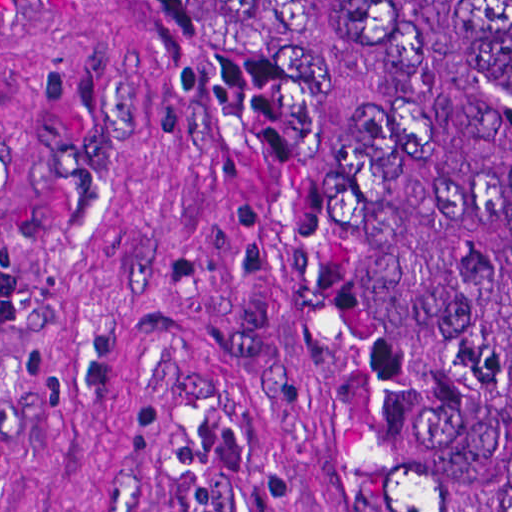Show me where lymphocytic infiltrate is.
I'll return each instance as SVG.
<instances>
[{"instance_id":"obj_1","label":"lymphocytic infiltrate","mask_w":512,"mask_h":512,"mask_svg":"<svg viewBox=\"0 0 512 512\" xmlns=\"http://www.w3.org/2000/svg\"><path fill=\"white\" fill-rule=\"evenodd\" d=\"M24 313V272L13 250L0 244V336Z\"/></svg>"}]
</instances>
